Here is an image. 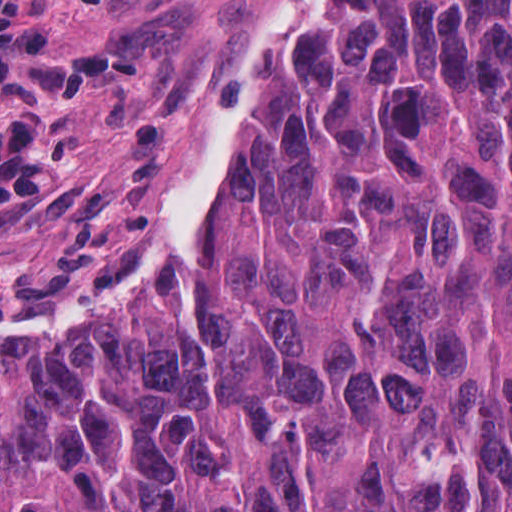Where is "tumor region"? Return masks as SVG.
<instances>
[{
	"instance_id": "1",
	"label": "tumor region",
	"mask_w": 512,
	"mask_h": 512,
	"mask_svg": "<svg viewBox=\"0 0 512 512\" xmlns=\"http://www.w3.org/2000/svg\"><path fill=\"white\" fill-rule=\"evenodd\" d=\"M0 512H512V0H218L89 215L0 249Z\"/></svg>"
}]
</instances>
